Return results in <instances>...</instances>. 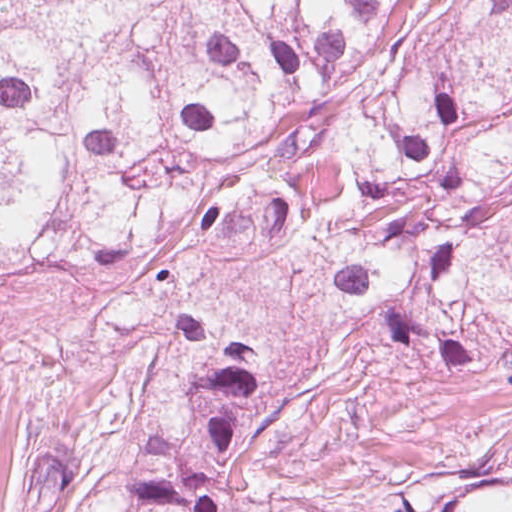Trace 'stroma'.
Masks as SVG:
<instances>
[{"label":"stroma","instance_id":"obj_1","mask_svg":"<svg viewBox=\"0 0 512 512\" xmlns=\"http://www.w3.org/2000/svg\"><path fill=\"white\" fill-rule=\"evenodd\" d=\"M256 351L247 487L230 512H407L512 437V387L230 251L160 257L0 301V512L37 507L44 440L102 437L199 351Z\"/></svg>","mask_w":512,"mask_h":512}]
</instances>
